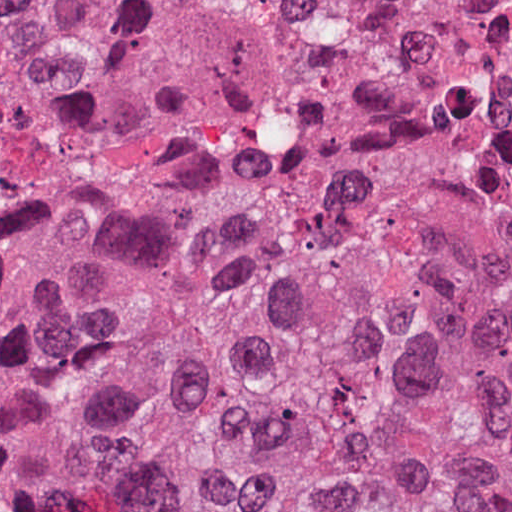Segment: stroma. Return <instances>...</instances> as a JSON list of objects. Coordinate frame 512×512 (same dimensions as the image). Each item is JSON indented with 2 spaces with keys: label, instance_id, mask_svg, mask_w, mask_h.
Segmentation results:
<instances>
[{
  "label": "stroma",
  "instance_id": "stroma-1",
  "mask_svg": "<svg viewBox=\"0 0 512 512\" xmlns=\"http://www.w3.org/2000/svg\"><path fill=\"white\" fill-rule=\"evenodd\" d=\"M278 0H134L95 57L0 90V233L150 197H248L281 147L235 139L286 68ZM0 512H30L0 483Z\"/></svg>",
  "mask_w": 512,
  "mask_h": 512
}]
</instances>
